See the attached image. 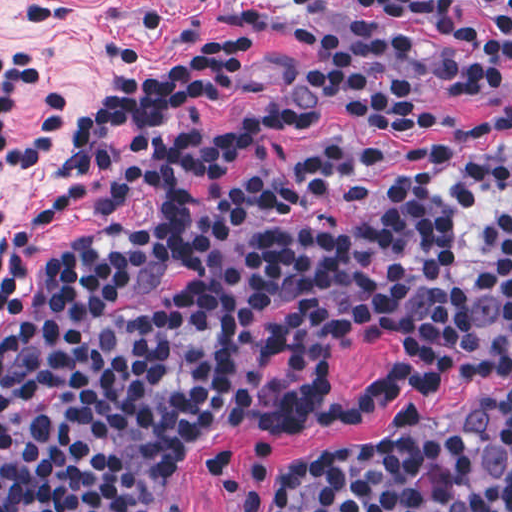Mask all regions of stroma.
Returning a JSON list of instances; mask_svg holds the SVG:
<instances>
[{
  "label": "stroma",
  "mask_w": 512,
  "mask_h": 512,
  "mask_svg": "<svg viewBox=\"0 0 512 512\" xmlns=\"http://www.w3.org/2000/svg\"><path fill=\"white\" fill-rule=\"evenodd\" d=\"M369 1L411 15L463 18L492 3L512 0H0V51L35 49L42 55L36 89L24 97L22 128L33 119L47 91H65L73 101L68 131L84 114L142 69L156 74L173 62L240 41L261 44L259 58L234 99H201L194 116L209 125H230L272 107L298 102L311 122L289 142L249 155L236 175L252 176L290 164L300 151L330 136H349L374 145H422L465 133L501 114L512 113V80L488 94L454 92L439 68L436 47L417 49L399 75L419 82L420 103L442 132L370 128L355 119L326 90L298 75L297 52L277 28L303 18L316 31V67H333L339 21L348 5ZM117 145L133 165L136 197L129 208L102 214H75L47 229L35 223L44 198L60 176V162L76 148L71 139L17 169L0 171V260L5 241L25 236L29 247L14 280L17 308L32 281L60 245L118 226H148L156 216L153 166L130 130L120 128ZM5 313L0 308V333ZM396 360L390 335L380 331L331 359L332 382L340 396L372 387ZM512 390V369L482 379L421 388L362 417L330 429L290 431L275 425H222L191 432L171 454L169 500L181 512H241L213 484L210 465L222 449L234 450L240 468L250 470L255 449L279 441L290 457H327L385 439L404 417L436 425L454 422L476 404Z\"/></svg>",
  "instance_id": "1"
}]
</instances>
